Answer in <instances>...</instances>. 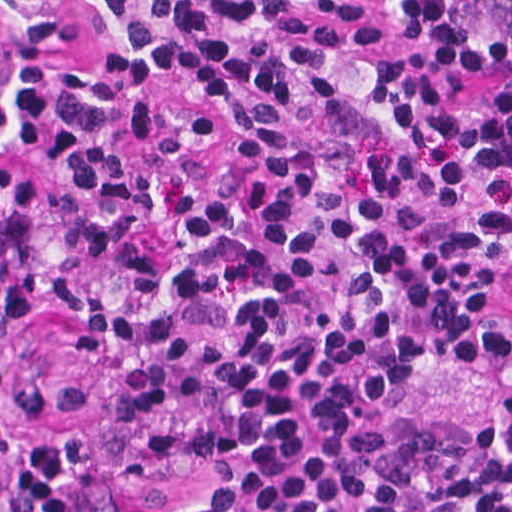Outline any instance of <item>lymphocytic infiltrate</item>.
Here are the masks:
<instances>
[{
  "label": "lymphocytic infiltrate",
  "mask_w": 512,
  "mask_h": 512,
  "mask_svg": "<svg viewBox=\"0 0 512 512\" xmlns=\"http://www.w3.org/2000/svg\"><path fill=\"white\" fill-rule=\"evenodd\" d=\"M0 271L171 512H512V384L384 410L512 351V0H0ZM84 406L0 353V512H81L99 449L18 433Z\"/></svg>",
  "instance_id": "lymphocytic-infiltrate-1"
}]
</instances>
